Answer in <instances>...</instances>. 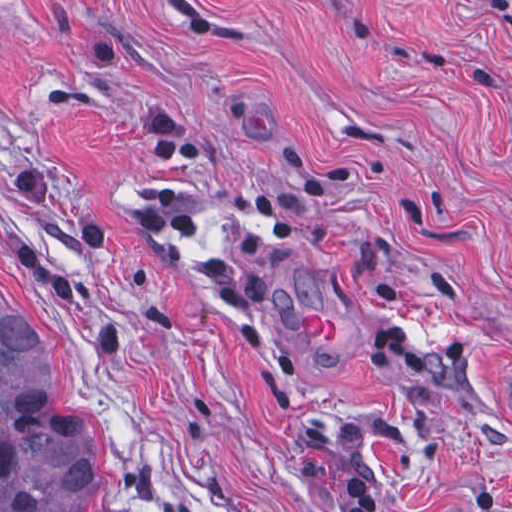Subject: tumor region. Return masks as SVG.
I'll return each mask as SVG.
<instances>
[{"mask_svg":"<svg viewBox=\"0 0 512 512\" xmlns=\"http://www.w3.org/2000/svg\"><path fill=\"white\" fill-rule=\"evenodd\" d=\"M0 512H99L95 411L1 305Z\"/></svg>","mask_w":512,"mask_h":512,"instance_id":"tumor-region-1","label":"tumor region"}]
</instances>
